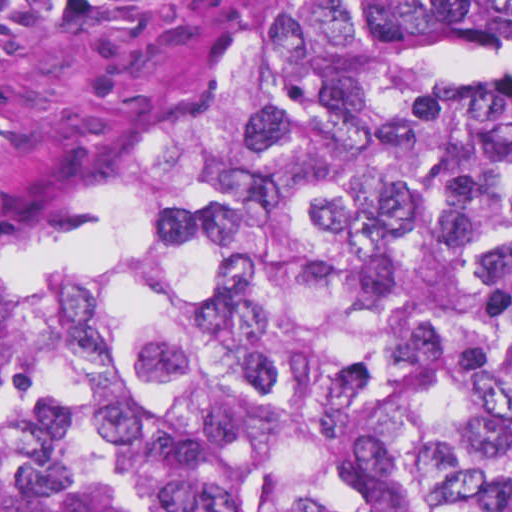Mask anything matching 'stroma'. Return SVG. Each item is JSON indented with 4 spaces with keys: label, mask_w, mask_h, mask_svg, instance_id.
<instances>
[{
    "label": "stroma",
    "mask_w": 512,
    "mask_h": 512,
    "mask_svg": "<svg viewBox=\"0 0 512 512\" xmlns=\"http://www.w3.org/2000/svg\"><path fill=\"white\" fill-rule=\"evenodd\" d=\"M282 0H0V221L200 107Z\"/></svg>",
    "instance_id": "stroma-1"
}]
</instances>
